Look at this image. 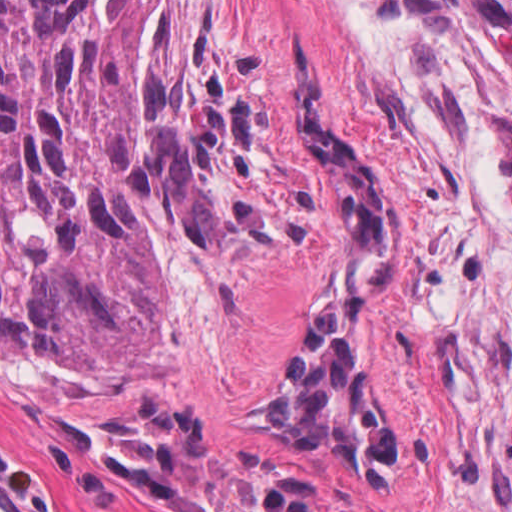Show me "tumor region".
<instances>
[{"instance_id": "1", "label": "tumor region", "mask_w": 512, "mask_h": 512, "mask_svg": "<svg viewBox=\"0 0 512 512\" xmlns=\"http://www.w3.org/2000/svg\"><path fill=\"white\" fill-rule=\"evenodd\" d=\"M287 44L294 138L337 214L342 259L274 406L245 434L344 479H383L400 417L376 309L400 261V187ZM484 129L512 198V142ZM307 219L254 79L199 0H0L1 351L76 383L131 384L161 342L167 240L274 248ZM90 437L156 495L215 512H349L224 464L161 397Z\"/></svg>"}]
</instances>
